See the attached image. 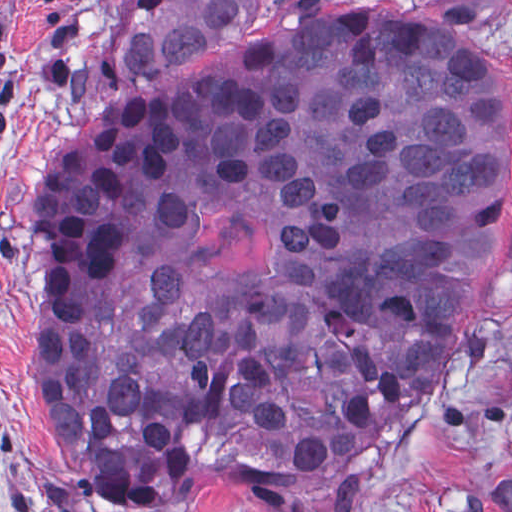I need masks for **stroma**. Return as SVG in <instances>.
<instances>
[{"label": "stroma", "instance_id": "35a3bbf8", "mask_svg": "<svg viewBox=\"0 0 512 512\" xmlns=\"http://www.w3.org/2000/svg\"><path fill=\"white\" fill-rule=\"evenodd\" d=\"M127 0H0V512H118L52 455L41 425L31 207L49 151L119 99L168 98L276 38L329 23L433 35L487 65L512 103V0H266L245 28L131 82L100 66ZM446 382L368 455L347 512H512V185ZM178 512H274L227 480Z\"/></svg>", "mask_w": 512, "mask_h": 512}]
</instances>
